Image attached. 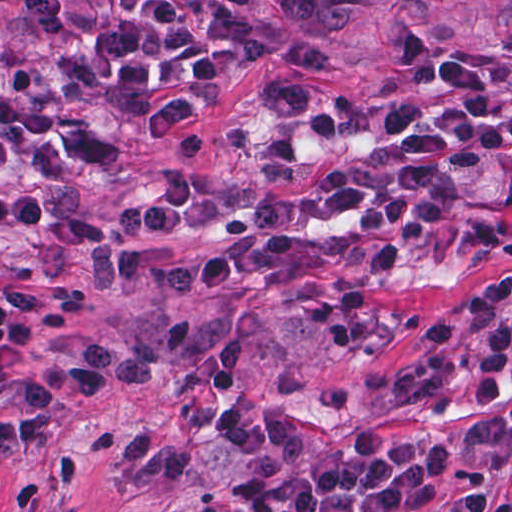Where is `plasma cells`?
I'll list each match as a JSON object with an SVG mask.
<instances>
[{
  "instance_id": "plasma-cells-1",
  "label": "plasma cells",
  "mask_w": 512,
  "mask_h": 512,
  "mask_svg": "<svg viewBox=\"0 0 512 512\" xmlns=\"http://www.w3.org/2000/svg\"><path fill=\"white\" fill-rule=\"evenodd\" d=\"M88 301L84 290L62 297L9 288L0 303V458L35 449L60 406L91 404L119 386L152 383V365L133 352L102 343L86 346L85 359L53 368L31 365L27 351L36 324L56 334L69 329Z\"/></svg>"
}]
</instances>
